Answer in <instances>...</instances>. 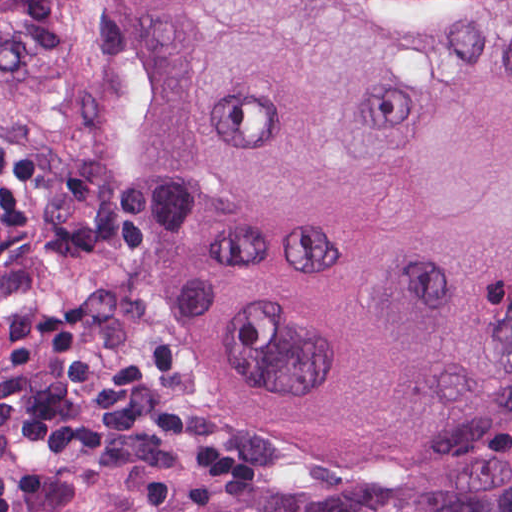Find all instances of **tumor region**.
I'll list each match as a JSON object with an SVG mask.
<instances>
[{
	"label": "tumor region",
	"instance_id": "obj_1",
	"mask_svg": "<svg viewBox=\"0 0 512 512\" xmlns=\"http://www.w3.org/2000/svg\"><path fill=\"white\" fill-rule=\"evenodd\" d=\"M138 0H0V337L77 262ZM139 267L217 405L335 466L512 412V0H142ZM78 512H512V431L373 494L112 491Z\"/></svg>",
	"mask_w": 512,
	"mask_h": 512
}]
</instances>
